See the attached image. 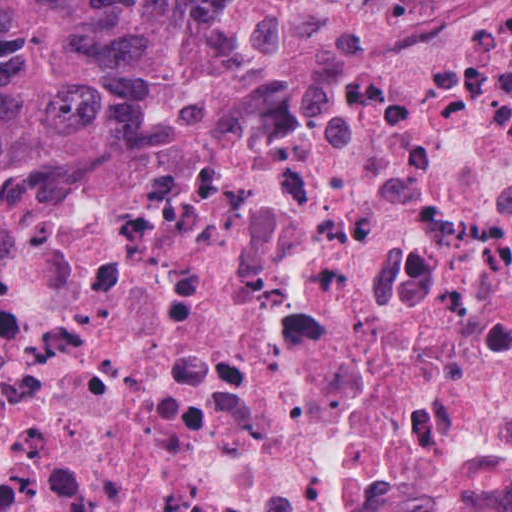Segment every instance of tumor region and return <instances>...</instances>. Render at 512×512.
Returning a JSON list of instances; mask_svg holds the SVG:
<instances>
[{
    "instance_id": "e687c5a6",
    "label": "tumor region",
    "mask_w": 512,
    "mask_h": 512,
    "mask_svg": "<svg viewBox=\"0 0 512 512\" xmlns=\"http://www.w3.org/2000/svg\"><path fill=\"white\" fill-rule=\"evenodd\" d=\"M284 0H0V239L109 127L199 113Z\"/></svg>"
}]
</instances>
